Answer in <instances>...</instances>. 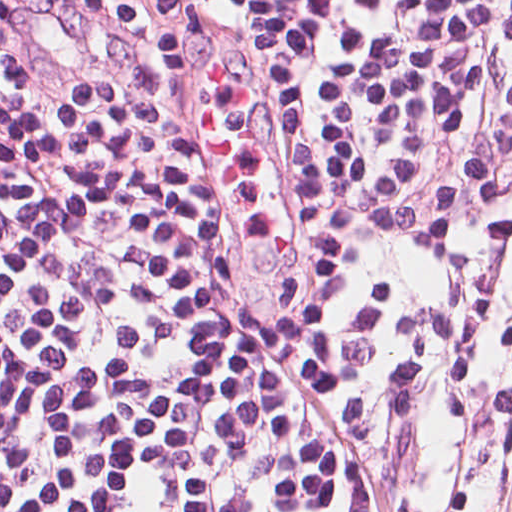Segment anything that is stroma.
<instances>
[{"label": "stroma", "instance_id": "1", "mask_svg": "<svg viewBox=\"0 0 512 512\" xmlns=\"http://www.w3.org/2000/svg\"><path fill=\"white\" fill-rule=\"evenodd\" d=\"M403 512H512V358L465 444L441 467L411 472Z\"/></svg>", "mask_w": 512, "mask_h": 512}]
</instances>
